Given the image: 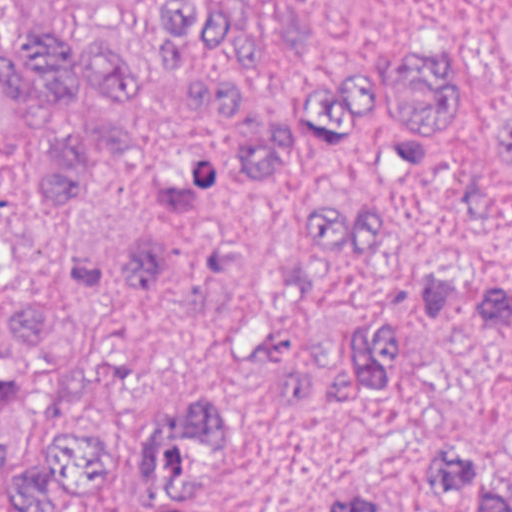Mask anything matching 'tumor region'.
Returning <instances> with one entry per match:
<instances>
[{"label":"tumor region","mask_w":512,"mask_h":512,"mask_svg":"<svg viewBox=\"0 0 512 512\" xmlns=\"http://www.w3.org/2000/svg\"><path fill=\"white\" fill-rule=\"evenodd\" d=\"M254 46L226 0H0V512H217L224 420L149 377L152 294L275 405L400 370L445 277L386 204L455 80L380 61L278 121L240 91ZM447 478L466 512H512V476Z\"/></svg>","instance_id":"e687c5a6"}]
</instances>
